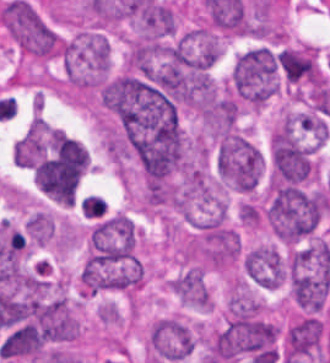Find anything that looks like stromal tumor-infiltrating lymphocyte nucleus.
<instances>
[{"label": "stromal tumor-infiltrating lymphocyte nucleus", "instance_id": "obj_1", "mask_svg": "<svg viewBox=\"0 0 330 363\" xmlns=\"http://www.w3.org/2000/svg\"><path fill=\"white\" fill-rule=\"evenodd\" d=\"M45 120H32L12 147L13 163L33 167L45 152Z\"/></svg>", "mask_w": 330, "mask_h": 363}, {"label": "stromal tumor-infiltrating lymphocyte nucleus", "instance_id": "obj_2", "mask_svg": "<svg viewBox=\"0 0 330 363\" xmlns=\"http://www.w3.org/2000/svg\"><path fill=\"white\" fill-rule=\"evenodd\" d=\"M105 206L106 203L103 197L95 194H88L80 201V209L82 213L90 217L102 213Z\"/></svg>", "mask_w": 330, "mask_h": 363}]
</instances>
